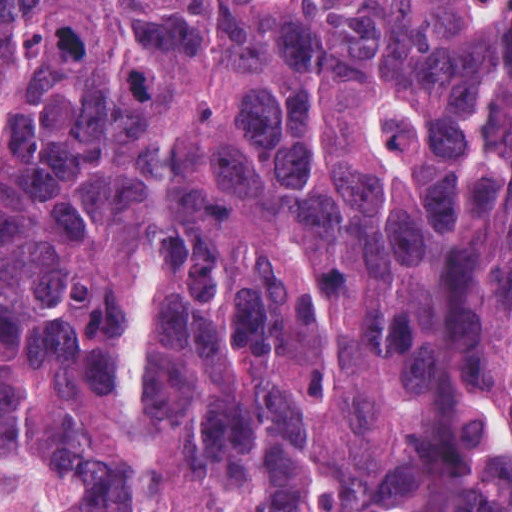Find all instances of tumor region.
Masks as SVG:
<instances>
[{
  "label": "tumor region",
  "instance_id": "e687c5a6",
  "mask_svg": "<svg viewBox=\"0 0 512 512\" xmlns=\"http://www.w3.org/2000/svg\"><path fill=\"white\" fill-rule=\"evenodd\" d=\"M76 512H512V0H0V460Z\"/></svg>",
  "mask_w": 512,
  "mask_h": 512
}]
</instances>
